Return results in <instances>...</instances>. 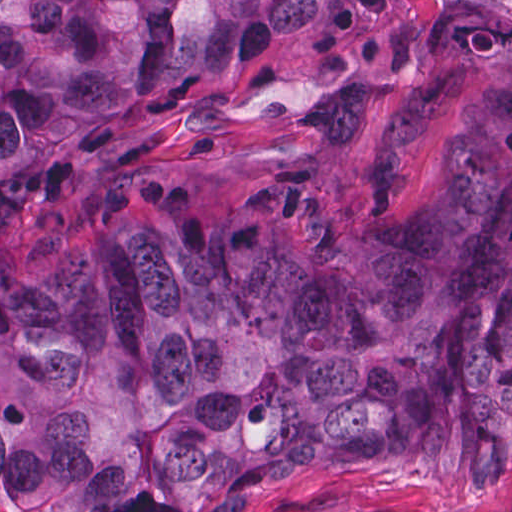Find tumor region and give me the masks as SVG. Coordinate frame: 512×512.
I'll use <instances>...</instances> for the list:
<instances>
[{
	"mask_svg": "<svg viewBox=\"0 0 512 512\" xmlns=\"http://www.w3.org/2000/svg\"><path fill=\"white\" fill-rule=\"evenodd\" d=\"M359 0H1V198L178 124ZM452 169L341 230L272 202L184 237L121 202L1 268V512H235L285 477L459 497L512 477V8H466L389 113L380 186L431 105Z\"/></svg>",
	"mask_w": 512,
	"mask_h": 512,
	"instance_id": "1",
	"label": "tumor region"
}]
</instances>
